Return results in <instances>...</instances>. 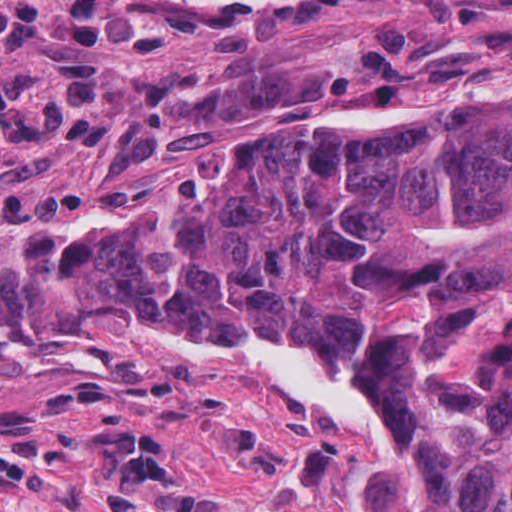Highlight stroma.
I'll return each mask as SVG.
<instances>
[{
	"instance_id": "35a3bbf8",
	"label": "stroma",
	"mask_w": 512,
	"mask_h": 512,
	"mask_svg": "<svg viewBox=\"0 0 512 512\" xmlns=\"http://www.w3.org/2000/svg\"><path fill=\"white\" fill-rule=\"evenodd\" d=\"M510 74L512 0H22L0 17V208L102 189L68 224L21 218L31 250L65 251L221 199L268 155L424 121L238 141L301 109ZM164 124L152 156L117 165ZM18 233L19 218L0 228V512H147L170 487L207 512H381L394 382L297 325L242 351L337 377L381 422L377 444L230 355L62 296Z\"/></svg>"
}]
</instances>
